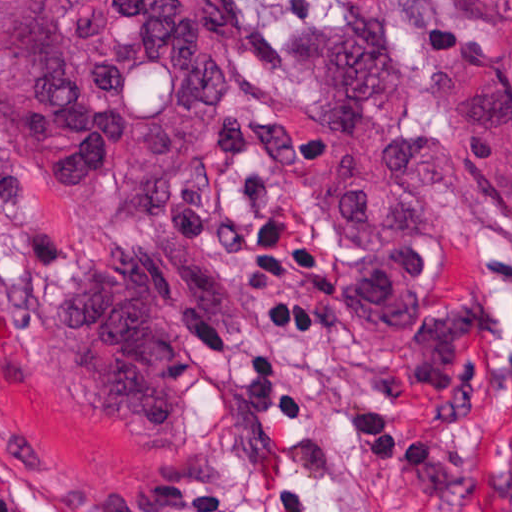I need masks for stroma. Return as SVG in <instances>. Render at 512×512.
<instances>
[{"instance_id":"stroma-1","label":"stroma","mask_w":512,"mask_h":512,"mask_svg":"<svg viewBox=\"0 0 512 512\" xmlns=\"http://www.w3.org/2000/svg\"><path fill=\"white\" fill-rule=\"evenodd\" d=\"M207 153L274 134L230 317L179 338L188 425L85 404L0 339V512L194 490L234 512H512V11L239 0ZM72 278L69 275L61 280Z\"/></svg>"}]
</instances>
